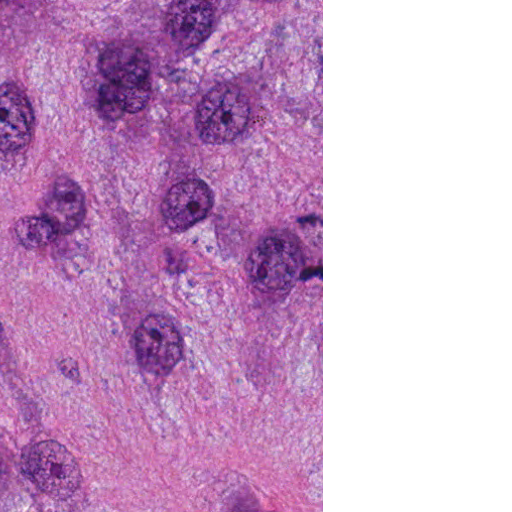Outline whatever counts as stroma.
Instances as JSON below:
<instances>
[{
	"mask_svg": "<svg viewBox=\"0 0 512 512\" xmlns=\"http://www.w3.org/2000/svg\"><path fill=\"white\" fill-rule=\"evenodd\" d=\"M161 512H323V0H161Z\"/></svg>",
	"mask_w": 512,
	"mask_h": 512,
	"instance_id": "obj_1",
	"label": "stroma"
}]
</instances>
